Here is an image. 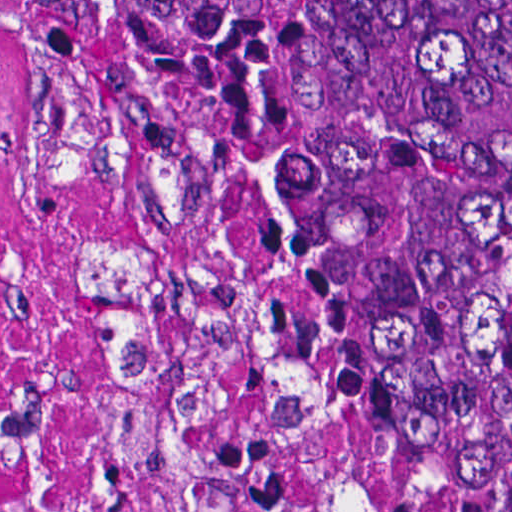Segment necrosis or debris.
<instances>
[{
  "label": "necrosis or debris",
  "instance_id": "obj_1",
  "mask_svg": "<svg viewBox=\"0 0 512 512\" xmlns=\"http://www.w3.org/2000/svg\"><path fill=\"white\" fill-rule=\"evenodd\" d=\"M488 437L290 340L189 163L0 0V512H463Z\"/></svg>",
  "mask_w": 512,
  "mask_h": 512
}]
</instances>
